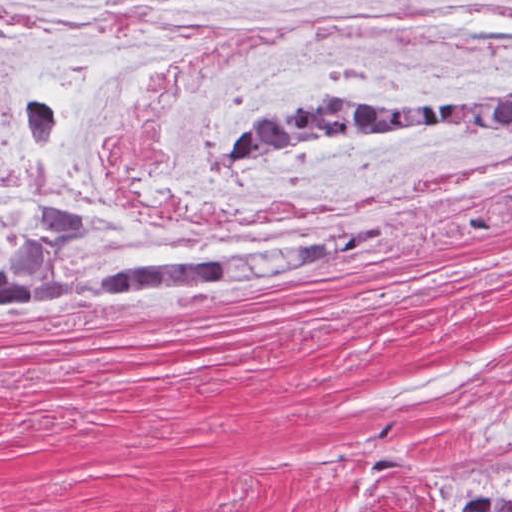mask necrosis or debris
<instances>
[{
    "label": "necrosis or debris",
    "instance_id": "necrosis-or-debris-1",
    "mask_svg": "<svg viewBox=\"0 0 512 512\" xmlns=\"http://www.w3.org/2000/svg\"><path fill=\"white\" fill-rule=\"evenodd\" d=\"M311 91H512V0H0V240L73 204L80 272L334 261L512 211V138L234 144Z\"/></svg>",
    "mask_w": 512,
    "mask_h": 512
}]
</instances>
